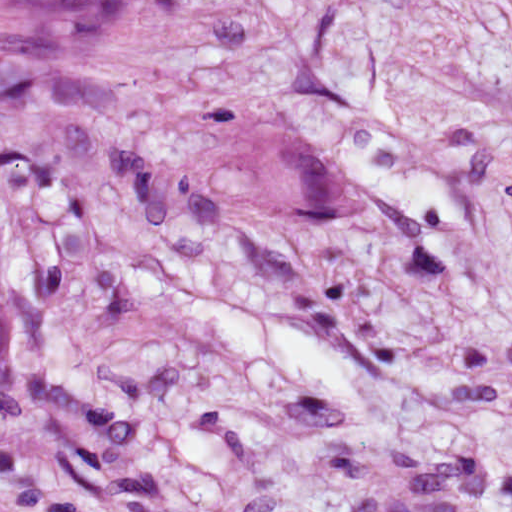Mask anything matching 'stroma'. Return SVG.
<instances>
[{
	"label": "stroma",
	"mask_w": 512,
	"mask_h": 512,
	"mask_svg": "<svg viewBox=\"0 0 512 512\" xmlns=\"http://www.w3.org/2000/svg\"><path fill=\"white\" fill-rule=\"evenodd\" d=\"M296 142L326 200L265 212ZM167 285L330 338L358 401ZM0 360L68 512H512V0L0 15Z\"/></svg>",
	"instance_id": "stroma-1"
}]
</instances>
